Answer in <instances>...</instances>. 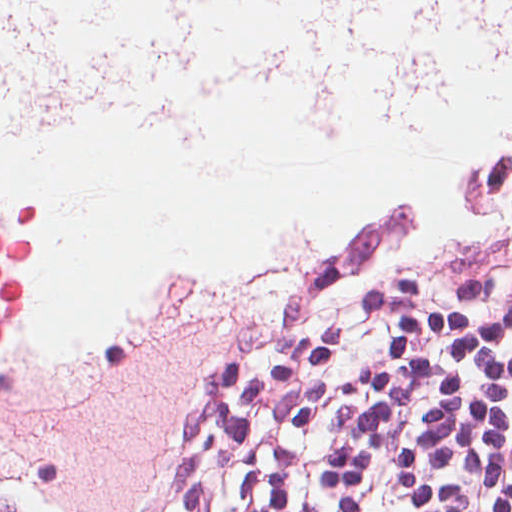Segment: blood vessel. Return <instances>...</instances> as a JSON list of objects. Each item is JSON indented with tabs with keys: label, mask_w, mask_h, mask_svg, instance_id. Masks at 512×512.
Here are the masks:
<instances>
[{
	"label": "blood vessel",
	"mask_w": 512,
	"mask_h": 512,
	"mask_svg": "<svg viewBox=\"0 0 512 512\" xmlns=\"http://www.w3.org/2000/svg\"><path fill=\"white\" fill-rule=\"evenodd\" d=\"M511 210L512 58L457 81L414 136L319 133L288 102L246 96L211 164L168 151L136 307L278 226L304 227L305 257L374 214L483 223Z\"/></svg>",
	"instance_id": "8fb6f2fc"
}]
</instances>
